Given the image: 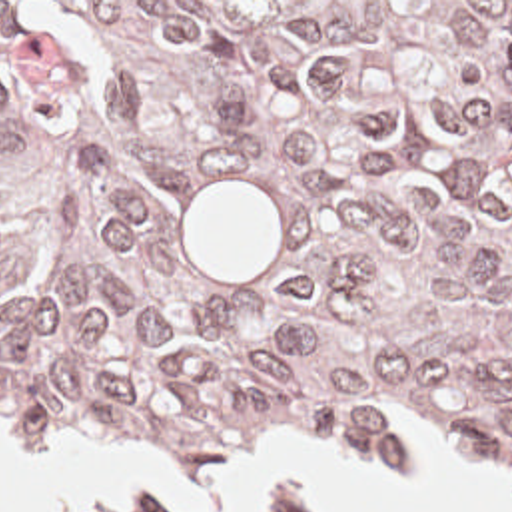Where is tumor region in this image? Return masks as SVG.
<instances>
[{
    "instance_id": "tumor-region-1",
    "label": "tumor region",
    "mask_w": 512,
    "mask_h": 512,
    "mask_svg": "<svg viewBox=\"0 0 512 512\" xmlns=\"http://www.w3.org/2000/svg\"><path fill=\"white\" fill-rule=\"evenodd\" d=\"M512 423V2H0V417Z\"/></svg>"
}]
</instances>
